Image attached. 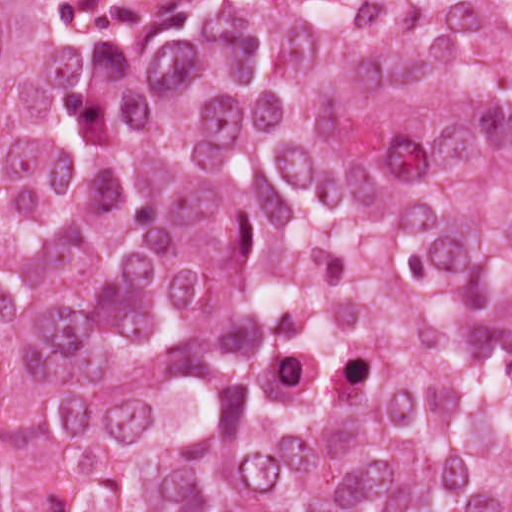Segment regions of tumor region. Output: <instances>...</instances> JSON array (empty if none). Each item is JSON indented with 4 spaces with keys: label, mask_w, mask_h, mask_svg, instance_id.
Here are the masks:
<instances>
[{
    "label": "tumor region",
    "mask_w": 512,
    "mask_h": 512,
    "mask_svg": "<svg viewBox=\"0 0 512 512\" xmlns=\"http://www.w3.org/2000/svg\"><path fill=\"white\" fill-rule=\"evenodd\" d=\"M0 512H512V1H0Z\"/></svg>",
    "instance_id": "1"
}]
</instances>
